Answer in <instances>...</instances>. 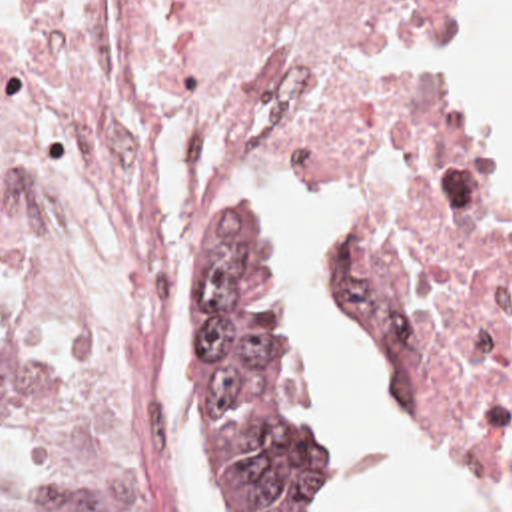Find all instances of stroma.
I'll use <instances>...</instances> for the list:
<instances>
[{"mask_svg":"<svg viewBox=\"0 0 512 512\" xmlns=\"http://www.w3.org/2000/svg\"><path fill=\"white\" fill-rule=\"evenodd\" d=\"M483 2L485 0H461L457 24H455V142H453L451 158H457L475 168L479 166L471 158L463 138V64H465V56L471 42L473 22ZM297 156L301 162V176L295 180V184L303 180H343L345 194H347V226L329 238L327 252H325V282H327L331 300L337 304V308L343 312L349 324L373 346V350L377 352L387 374L391 377L401 401L405 403V407L409 409L417 425L423 429V433L431 437L435 443H439L443 449L459 455L463 461L475 467L487 479V483L501 495V499L507 503L509 511L512 512V475L511 471L505 467V463L501 461V457L495 455L491 449H487L483 443H479L475 437H471L441 405L409 389L385 324L359 300L353 264L359 254L361 242L365 238L377 196L387 192L393 186H369L357 180H349L325 170L323 166H319L317 162L309 160L303 154H297ZM489 184H491L493 200L512 234V198L509 194H505L493 180H489ZM145 294H147V306H149V280L145 284ZM0 312L6 318H10L27 336L29 350H31L29 370L23 381L20 397L0 417L2 457H6L10 463H14L20 469L53 479L57 483L69 485L85 493L103 512H117L99 477L61 471L29 451V411L47 389L53 356L27 330L16 306L2 290H0ZM301 346L307 356L303 334H301ZM501 370L512 375V240L503 294H501Z\"/></svg>","mask_w":512,"mask_h":512,"instance_id":"35a3bbf8","label":"stroma"}]
</instances>
